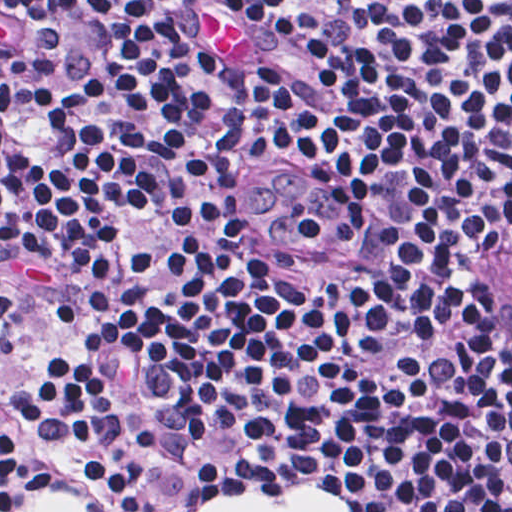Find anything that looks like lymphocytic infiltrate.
Returning <instances> with one entry per match:
<instances>
[{
    "label": "lymphocytic infiltrate",
    "instance_id": "obj_1",
    "mask_svg": "<svg viewBox=\"0 0 512 512\" xmlns=\"http://www.w3.org/2000/svg\"><path fill=\"white\" fill-rule=\"evenodd\" d=\"M256 61L206 47L228 6ZM512 213V0H0V271L61 322L0 376V512L296 474L512 512L471 225Z\"/></svg>",
    "mask_w": 512,
    "mask_h": 512
}]
</instances>
